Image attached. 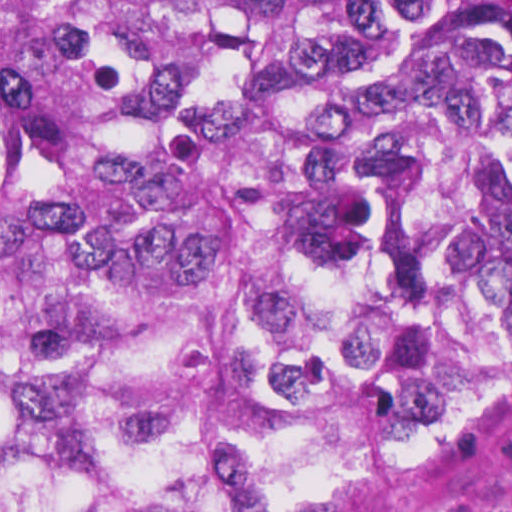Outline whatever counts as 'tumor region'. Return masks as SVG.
Instances as JSON below:
<instances>
[{
  "instance_id": "e687c5a6",
  "label": "tumor region",
  "mask_w": 512,
  "mask_h": 512,
  "mask_svg": "<svg viewBox=\"0 0 512 512\" xmlns=\"http://www.w3.org/2000/svg\"><path fill=\"white\" fill-rule=\"evenodd\" d=\"M512 411V1H0V512H375Z\"/></svg>"
}]
</instances>
